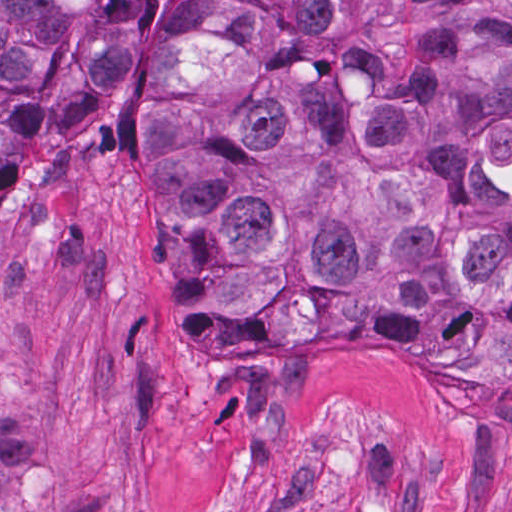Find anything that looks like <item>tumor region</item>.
I'll return each instance as SVG.
<instances>
[{
    "label": "tumor region",
    "mask_w": 512,
    "mask_h": 512,
    "mask_svg": "<svg viewBox=\"0 0 512 512\" xmlns=\"http://www.w3.org/2000/svg\"><path fill=\"white\" fill-rule=\"evenodd\" d=\"M151 0H0V170L114 90ZM126 136L208 356H441L512 404V0H175ZM53 454L0 395V512Z\"/></svg>",
    "instance_id": "obj_1"
}]
</instances>
